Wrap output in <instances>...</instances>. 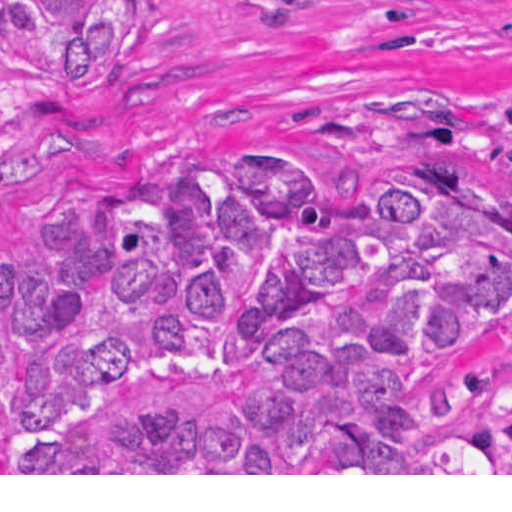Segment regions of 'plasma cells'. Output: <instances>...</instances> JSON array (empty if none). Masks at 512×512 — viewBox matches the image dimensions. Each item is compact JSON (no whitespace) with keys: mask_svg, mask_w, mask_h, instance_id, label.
Instances as JSON below:
<instances>
[{"mask_svg":"<svg viewBox=\"0 0 512 512\" xmlns=\"http://www.w3.org/2000/svg\"><path fill=\"white\" fill-rule=\"evenodd\" d=\"M497 114L504 122L512 140V93L497 99Z\"/></svg>","mask_w":512,"mask_h":512,"instance_id":"9512152a","label":"plasma cells"}]
</instances>
